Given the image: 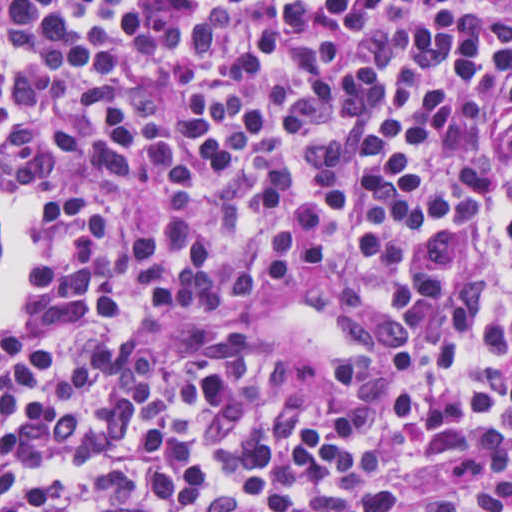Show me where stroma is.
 <instances>
[{
  "instance_id": "35a3bbf8",
  "label": "stroma",
  "mask_w": 512,
  "mask_h": 512,
  "mask_svg": "<svg viewBox=\"0 0 512 512\" xmlns=\"http://www.w3.org/2000/svg\"><path fill=\"white\" fill-rule=\"evenodd\" d=\"M348 290L349 279L342 275L301 270L282 284L252 291L228 305L167 311L165 321L184 331H227L250 341L265 363L283 372L286 384L302 400L323 402L332 367L363 353L356 311L345 297ZM31 310L30 299L8 329Z\"/></svg>"
}]
</instances>
